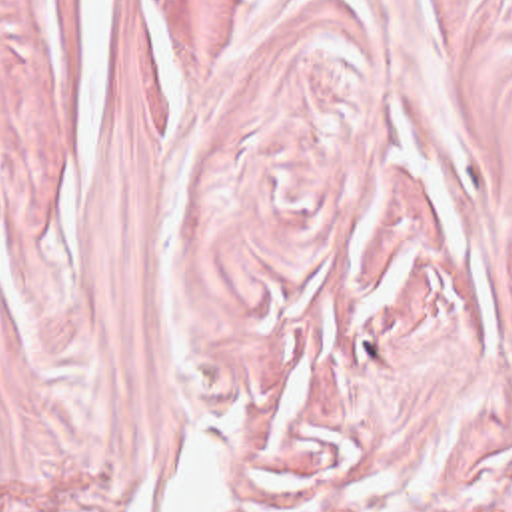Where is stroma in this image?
I'll return each mask as SVG.
<instances>
[{"mask_svg":"<svg viewBox=\"0 0 512 512\" xmlns=\"http://www.w3.org/2000/svg\"><path fill=\"white\" fill-rule=\"evenodd\" d=\"M512 512V0H0V512Z\"/></svg>","mask_w":512,"mask_h":512,"instance_id":"35a3bbf8","label":"stroma"}]
</instances>
